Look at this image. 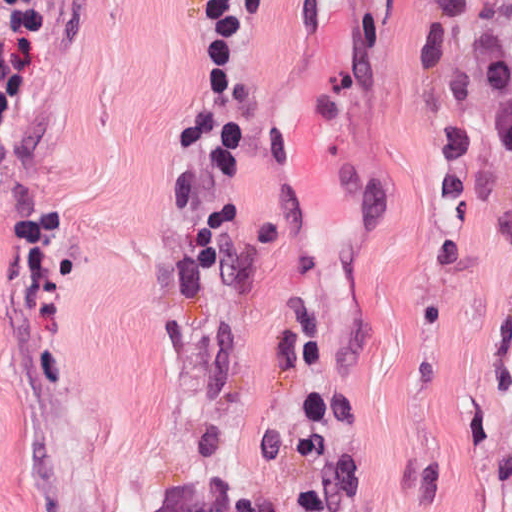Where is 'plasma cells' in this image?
<instances>
[{
	"mask_svg": "<svg viewBox=\"0 0 512 512\" xmlns=\"http://www.w3.org/2000/svg\"><path fill=\"white\" fill-rule=\"evenodd\" d=\"M413 6V66L420 75L446 61L454 30L467 32L449 68L434 132L438 192L465 200L480 145L512 157V27L475 0H413ZM298 398L304 428L273 432L255 444L260 459L294 472L295 490L239 494L221 468L225 434L213 428L203 439L198 467L171 488L156 512H341L352 486L333 437L327 362L316 348L300 355Z\"/></svg>",
	"mask_w": 512,
	"mask_h": 512,
	"instance_id": "obj_1",
	"label": "plasma cells"
}]
</instances>
